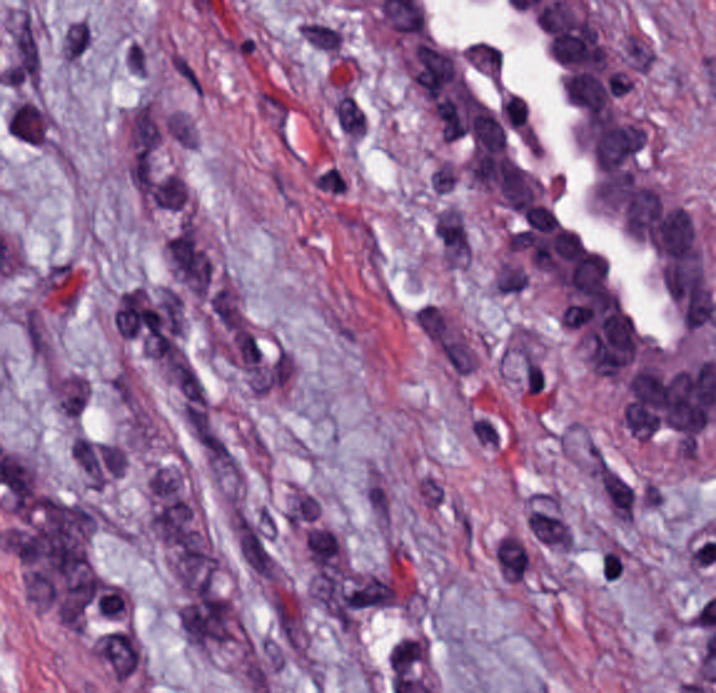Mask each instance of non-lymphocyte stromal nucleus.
<instances>
[{
  "label": "non-lymphocyte stromal nucleus",
  "instance_id": "obj_1",
  "mask_svg": "<svg viewBox=\"0 0 716 693\" xmlns=\"http://www.w3.org/2000/svg\"><path fill=\"white\" fill-rule=\"evenodd\" d=\"M166 297H227V221H166Z\"/></svg>",
  "mask_w": 716,
  "mask_h": 693
},
{
  "label": "non-lymphocyte stromal nucleus",
  "instance_id": "obj_2",
  "mask_svg": "<svg viewBox=\"0 0 716 693\" xmlns=\"http://www.w3.org/2000/svg\"><path fill=\"white\" fill-rule=\"evenodd\" d=\"M118 175H164V89H118Z\"/></svg>",
  "mask_w": 716,
  "mask_h": 693
},
{
  "label": "non-lymphocyte stromal nucleus",
  "instance_id": "obj_3",
  "mask_svg": "<svg viewBox=\"0 0 716 693\" xmlns=\"http://www.w3.org/2000/svg\"><path fill=\"white\" fill-rule=\"evenodd\" d=\"M168 444H224V378H168Z\"/></svg>",
  "mask_w": 716,
  "mask_h": 693
},
{
  "label": "non-lymphocyte stromal nucleus",
  "instance_id": "obj_4",
  "mask_svg": "<svg viewBox=\"0 0 716 693\" xmlns=\"http://www.w3.org/2000/svg\"><path fill=\"white\" fill-rule=\"evenodd\" d=\"M425 275H476V204H425Z\"/></svg>",
  "mask_w": 716,
  "mask_h": 693
},
{
  "label": "non-lymphocyte stromal nucleus",
  "instance_id": "obj_5",
  "mask_svg": "<svg viewBox=\"0 0 716 693\" xmlns=\"http://www.w3.org/2000/svg\"><path fill=\"white\" fill-rule=\"evenodd\" d=\"M6 87H42V2H6Z\"/></svg>",
  "mask_w": 716,
  "mask_h": 693
},
{
  "label": "non-lymphocyte stromal nucleus",
  "instance_id": "obj_6",
  "mask_svg": "<svg viewBox=\"0 0 716 693\" xmlns=\"http://www.w3.org/2000/svg\"><path fill=\"white\" fill-rule=\"evenodd\" d=\"M241 587H287V521H241Z\"/></svg>",
  "mask_w": 716,
  "mask_h": 693
},
{
  "label": "non-lymphocyte stromal nucleus",
  "instance_id": "obj_7",
  "mask_svg": "<svg viewBox=\"0 0 716 693\" xmlns=\"http://www.w3.org/2000/svg\"><path fill=\"white\" fill-rule=\"evenodd\" d=\"M138 222H194V171H138Z\"/></svg>",
  "mask_w": 716,
  "mask_h": 693
},
{
  "label": "non-lymphocyte stromal nucleus",
  "instance_id": "obj_8",
  "mask_svg": "<svg viewBox=\"0 0 716 693\" xmlns=\"http://www.w3.org/2000/svg\"><path fill=\"white\" fill-rule=\"evenodd\" d=\"M271 522H327V471H271Z\"/></svg>",
  "mask_w": 716,
  "mask_h": 693
},
{
  "label": "non-lymphocyte stromal nucleus",
  "instance_id": "obj_9",
  "mask_svg": "<svg viewBox=\"0 0 716 693\" xmlns=\"http://www.w3.org/2000/svg\"><path fill=\"white\" fill-rule=\"evenodd\" d=\"M178 646H234V601H178Z\"/></svg>",
  "mask_w": 716,
  "mask_h": 693
},
{
  "label": "non-lymphocyte stromal nucleus",
  "instance_id": "obj_10",
  "mask_svg": "<svg viewBox=\"0 0 716 693\" xmlns=\"http://www.w3.org/2000/svg\"><path fill=\"white\" fill-rule=\"evenodd\" d=\"M46 407L68 428L82 429L92 378L72 363L43 371Z\"/></svg>",
  "mask_w": 716,
  "mask_h": 693
},
{
  "label": "non-lymphocyte stromal nucleus",
  "instance_id": "obj_11",
  "mask_svg": "<svg viewBox=\"0 0 716 693\" xmlns=\"http://www.w3.org/2000/svg\"><path fill=\"white\" fill-rule=\"evenodd\" d=\"M116 80H162V29H116Z\"/></svg>",
  "mask_w": 716,
  "mask_h": 693
},
{
  "label": "non-lymphocyte stromal nucleus",
  "instance_id": "obj_12",
  "mask_svg": "<svg viewBox=\"0 0 716 693\" xmlns=\"http://www.w3.org/2000/svg\"><path fill=\"white\" fill-rule=\"evenodd\" d=\"M86 654L111 678L125 680L143 663L144 654L132 626L96 633Z\"/></svg>",
  "mask_w": 716,
  "mask_h": 693
},
{
  "label": "non-lymphocyte stromal nucleus",
  "instance_id": "obj_13",
  "mask_svg": "<svg viewBox=\"0 0 716 693\" xmlns=\"http://www.w3.org/2000/svg\"><path fill=\"white\" fill-rule=\"evenodd\" d=\"M525 549H571V503H525Z\"/></svg>",
  "mask_w": 716,
  "mask_h": 693
},
{
  "label": "non-lymphocyte stromal nucleus",
  "instance_id": "obj_14",
  "mask_svg": "<svg viewBox=\"0 0 716 693\" xmlns=\"http://www.w3.org/2000/svg\"><path fill=\"white\" fill-rule=\"evenodd\" d=\"M306 564H351V518H306Z\"/></svg>",
  "mask_w": 716,
  "mask_h": 693
},
{
  "label": "non-lymphocyte stromal nucleus",
  "instance_id": "obj_15",
  "mask_svg": "<svg viewBox=\"0 0 716 693\" xmlns=\"http://www.w3.org/2000/svg\"><path fill=\"white\" fill-rule=\"evenodd\" d=\"M63 57H104V7H63Z\"/></svg>",
  "mask_w": 716,
  "mask_h": 693
},
{
  "label": "non-lymphocyte stromal nucleus",
  "instance_id": "obj_16",
  "mask_svg": "<svg viewBox=\"0 0 716 693\" xmlns=\"http://www.w3.org/2000/svg\"><path fill=\"white\" fill-rule=\"evenodd\" d=\"M493 582H529V536H493Z\"/></svg>",
  "mask_w": 716,
  "mask_h": 693
},
{
  "label": "non-lymphocyte stromal nucleus",
  "instance_id": "obj_17",
  "mask_svg": "<svg viewBox=\"0 0 716 693\" xmlns=\"http://www.w3.org/2000/svg\"><path fill=\"white\" fill-rule=\"evenodd\" d=\"M171 90H202V44H171Z\"/></svg>",
  "mask_w": 716,
  "mask_h": 693
},
{
  "label": "non-lymphocyte stromal nucleus",
  "instance_id": "obj_18",
  "mask_svg": "<svg viewBox=\"0 0 716 693\" xmlns=\"http://www.w3.org/2000/svg\"><path fill=\"white\" fill-rule=\"evenodd\" d=\"M168 147H194V96H168Z\"/></svg>",
  "mask_w": 716,
  "mask_h": 693
}]
</instances>
